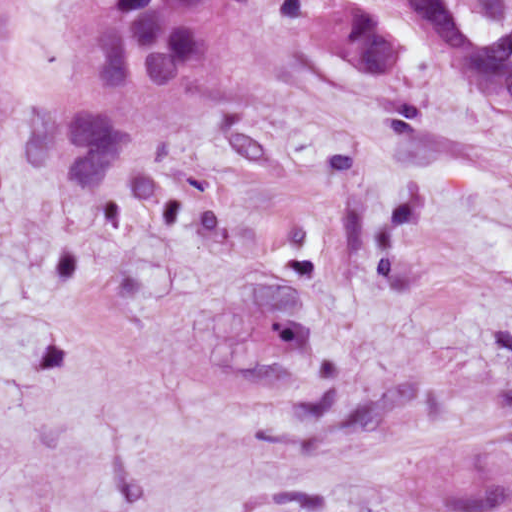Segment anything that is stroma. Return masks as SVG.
<instances>
[{
    "label": "stroma",
    "mask_w": 512,
    "mask_h": 512,
    "mask_svg": "<svg viewBox=\"0 0 512 512\" xmlns=\"http://www.w3.org/2000/svg\"><path fill=\"white\" fill-rule=\"evenodd\" d=\"M248 0L101 186L29 162L74 0H0V512H512V112Z\"/></svg>",
    "instance_id": "1"
}]
</instances>
